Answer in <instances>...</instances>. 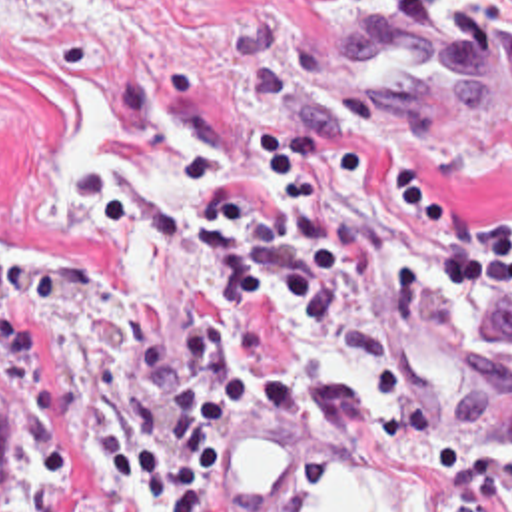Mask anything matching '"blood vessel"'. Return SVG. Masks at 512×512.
Instances as JSON below:
<instances>
[{"label":"blood vessel","instance_id":"8fb6f2fc","mask_svg":"<svg viewBox=\"0 0 512 512\" xmlns=\"http://www.w3.org/2000/svg\"><path fill=\"white\" fill-rule=\"evenodd\" d=\"M348 57L386 103L480 123H512V49L468 29L368 13ZM512 406V377L508 379Z\"/></svg>","mask_w":512,"mask_h":512}]
</instances>
